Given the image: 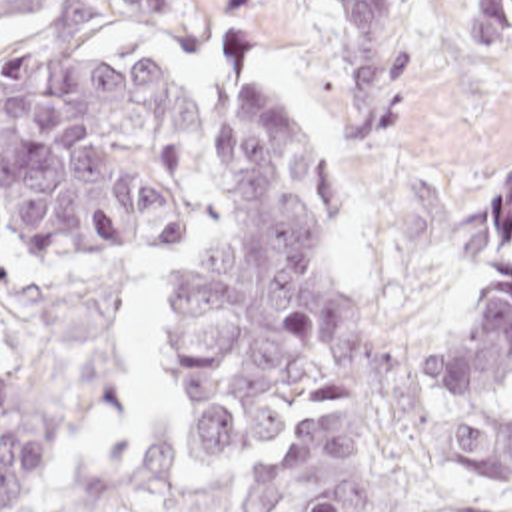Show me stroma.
<instances>
[{
  "instance_id": "1",
  "label": "stroma",
  "mask_w": 512,
  "mask_h": 512,
  "mask_svg": "<svg viewBox=\"0 0 512 512\" xmlns=\"http://www.w3.org/2000/svg\"><path fill=\"white\" fill-rule=\"evenodd\" d=\"M400 121L346 143L342 29L332 0H182L172 29H0V73L34 47L126 43L196 89V197L184 243L128 265L30 255L0 217L6 379L46 413V452L14 512H260L280 441L228 462L182 427L170 283L222 233L216 129L228 81L296 105L348 187L326 265L348 309L396 341L439 339L512 277V47L455 39L435 0H401ZM493 399L512 403V389ZM356 409L368 454L398 470L413 512H512V482L421 472L390 456L352 365L316 405Z\"/></svg>"
}]
</instances>
